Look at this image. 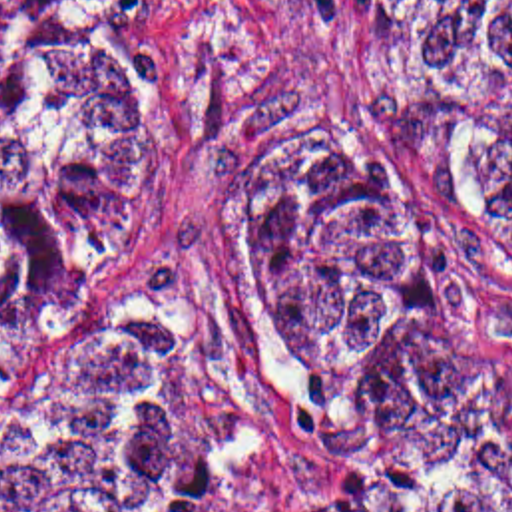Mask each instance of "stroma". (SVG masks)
Masks as SVG:
<instances>
[{"label": "stroma", "mask_w": 512, "mask_h": 512, "mask_svg": "<svg viewBox=\"0 0 512 512\" xmlns=\"http://www.w3.org/2000/svg\"><path fill=\"white\" fill-rule=\"evenodd\" d=\"M130 49L184 93V155L136 243L76 294L48 352L30 420L0 430V474L42 460L86 406L108 314L144 302L188 308L251 346L208 273L204 199L218 167L273 131L345 135L383 157L395 191L423 217L453 284L512 350V253L480 219L441 199L417 165L367 125L371 0H112ZM401 474L512 484V430Z\"/></svg>", "instance_id": "35a3bbf8"}]
</instances>
